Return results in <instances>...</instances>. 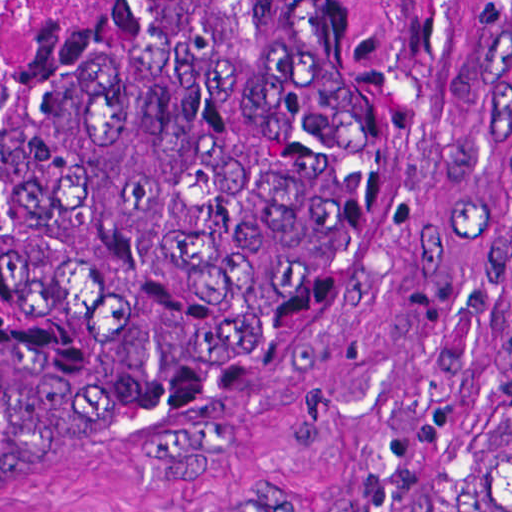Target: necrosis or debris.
<instances>
[{
    "label": "necrosis or debris",
    "instance_id": "1",
    "mask_svg": "<svg viewBox=\"0 0 512 512\" xmlns=\"http://www.w3.org/2000/svg\"><path fill=\"white\" fill-rule=\"evenodd\" d=\"M47 0H0V57L24 34Z\"/></svg>",
    "mask_w": 512,
    "mask_h": 512
}]
</instances>
